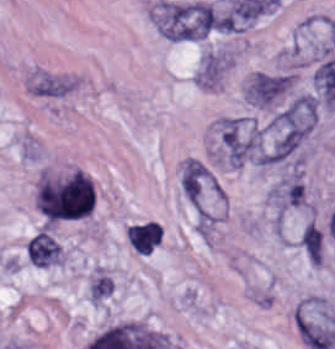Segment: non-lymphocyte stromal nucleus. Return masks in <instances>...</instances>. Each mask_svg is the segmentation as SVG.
Listing matches in <instances>:
<instances>
[{"label": "non-lymphocyte stromal nucleus", "instance_id": "obj_1", "mask_svg": "<svg viewBox=\"0 0 335 349\" xmlns=\"http://www.w3.org/2000/svg\"><path fill=\"white\" fill-rule=\"evenodd\" d=\"M151 16L167 39L197 40L226 32V15L203 1L161 0Z\"/></svg>", "mask_w": 335, "mask_h": 349}, {"label": "non-lymphocyte stromal nucleus", "instance_id": "obj_2", "mask_svg": "<svg viewBox=\"0 0 335 349\" xmlns=\"http://www.w3.org/2000/svg\"><path fill=\"white\" fill-rule=\"evenodd\" d=\"M297 328L305 343L318 349L335 346V321L327 313L298 303Z\"/></svg>", "mask_w": 335, "mask_h": 349}, {"label": "non-lymphocyte stromal nucleus", "instance_id": "obj_3", "mask_svg": "<svg viewBox=\"0 0 335 349\" xmlns=\"http://www.w3.org/2000/svg\"><path fill=\"white\" fill-rule=\"evenodd\" d=\"M292 78L287 74L259 71L244 88L245 97L257 105H271L290 87Z\"/></svg>", "mask_w": 335, "mask_h": 349}, {"label": "non-lymphocyte stromal nucleus", "instance_id": "obj_4", "mask_svg": "<svg viewBox=\"0 0 335 349\" xmlns=\"http://www.w3.org/2000/svg\"><path fill=\"white\" fill-rule=\"evenodd\" d=\"M271 198L276 209L288 210L303 206L306 196L303 178L298 169H291L272 187Z\"/></svg>", "mask_w": 335, "mask_h": 349}, {"label": "non-lymphocyte stromal nucleus", "instance_id": "obj_5", "mask_svg": "<svg viewBox=\"0 0 335 349\" xmlns=\"http://www.w3.org/2000/svg\"><path fill=\"white\" fill-rule=\"evenodd\" d=\"M29 261L39 266L61 263V248L46 229L34 234L26 245Z\"/></svg>", "mask_w": 335, "mask_h": 349}, {"label": "non-lymphocyte stromal nucleus", "instance_id": "obj_6", "mask_svg": "<svg viewBox=\"0 0 335 349\" xmlns=\"http://www.w3.org/2000/svg\"><path fill=\"white\" fill-rule=\"evenodd\" d=\"M129 245L140 255H149L161 241L160 227L155 220L131 223L127 226Z\"/></svg>", "mask_w": 335, "mask_h": 349}, {"label": "non-lymphocyte stromal nucleus", "instance_id": "obj_7", "mask_svg": "<svg viewBox=\"0 0 335 349\" xmlns=\"http://www.w3.org/2000/svg\"><path fill=\"white\" fill-rule=\"evenodd\" d=\"M73 81L50 73H36L31 80L33 93L44 96H63L71 88Z\"/></svg>", "mask_w": 335, "mask_h": 349}, {"label": "non-lymphocyte stromal nucleus", "instance_id": "obj_8", "mask_svg": "<svg viewBox=\"0 0 335 349\" xmlns=\"http://www.w3.org/2000/svg\"><path fill=\"white\" fill-rule=\"evenodd\" d=\"M302 242L313 262L321 264L323 236L315 222L312 221L304 228Z\"/></svg>", "mask_w": 335, "mask_h": 349}, {"label": "non-lymphocyte stromal nucleus", "instance_id": "obj_9", "mask_svg": "<svg viewBox=\"0 0 335 349\" xmlns=\"http://www.w3.org/2000/svg\"><path fill=\"white\" fill-rule=\"evenodd\" d=\"M113 278L112 276L97 271L91 281L90 298L91 301H99L105 296L112 293Z\"/></svg>", "mask_w": 335, "mask_h": 349}]
</instances>
